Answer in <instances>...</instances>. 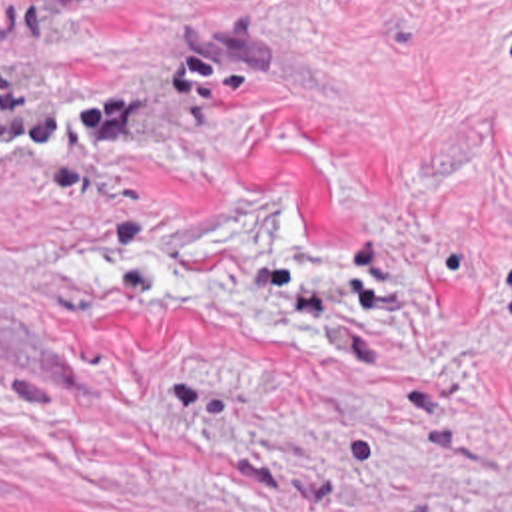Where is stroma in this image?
<instances>
[{
	"label": "stroma",
	"mask_w": 512,
	"mask_h": 512,
	"mask_svg": "<svg viewBox=\"0 0 512 512\" xmlns=\"http://www.w3.org/2000/svg\"><path fill=\"white\" fill-rule=\"evenodd\" d=\"M0 512H512V0H0Z\"/></svg>",
	"instance_id": "35a3bbf8"
}]
</instances>
